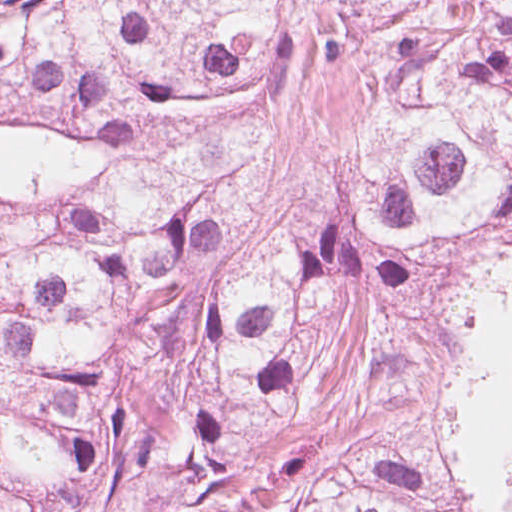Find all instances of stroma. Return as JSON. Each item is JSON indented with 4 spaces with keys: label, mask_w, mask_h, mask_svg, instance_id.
<instances>
[{
    "label": "stroma",
    "mask_w": 512,
    "mask_h": 512,
    "mask_svg": "<svg viewBox=\"0 0 512 512\" xmlns=\"http://www.w3.org/2000/svg\"><path fill=\"white\" fill-rule=\"evenodd\" d=\"M362 414V391L324 379V394L314 410L235 467L218 498L219 511L318 483L349 450ZM436 418L454 475L480 510L512 512V440Z\"/></svg>",
    "instance_id": "obj_1"
}]
</instances>
